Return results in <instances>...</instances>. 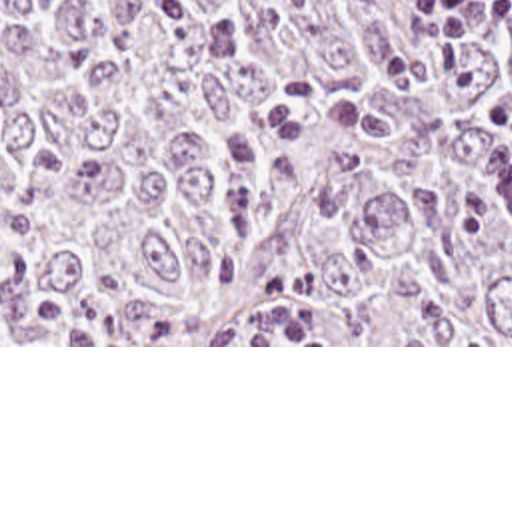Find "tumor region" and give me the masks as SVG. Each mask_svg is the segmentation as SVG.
Returning <instances> with one entry per match:
<instances>
[{
  "mask_svg": "<svg viewBox=\"0 0 512 512\" xmlns=\"http://www.w3.org/2000/svg\"><path fill=\"white\" fill-rule=\"evenodd\" d=\"M412 0H0V345H512L511 24Z\"/></svg>",
  "mask_w": 512,
  "mask_h": 512,
  "instance_id": "obj_1",
  "label": "tumor region"
}]
</instances>
